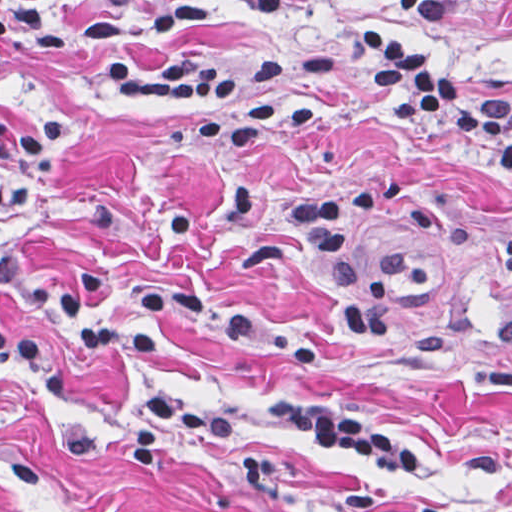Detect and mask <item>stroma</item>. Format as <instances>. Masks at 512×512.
Here are the masks:
<instances>
[{
  "label": "stroma",
  "mask_w": 512,
  "mask_h": 512,
  "mask_svg": "<svg viewBox=\"0 0 512 512\" xmlns=\"http://www.w3.org/2000/svg\"><path fill=\"white\" fill-rule=\"evenodd\" d=\"M151 1L46 0L41 35L0 49V122L69 110L76 124L54 177L13 211L12 240L58 268L108 267V300L131 318L159 279L203 282L208 300L144 360L60 356V389L0 366V512H512V178L488 177L459 129L399 120L344 62L250 89L312 106L308 129L213 152L190 113L119 95L102 42L82 38L78 25ZM212 2L117 44L138 68H247L380 29L512 100V0L452 25L429 23L420 0ZM151 385L235 428L170 436L150 469H130L121 442ZM269 394L354 415L440 469L322 450Z\"/></svg>",
  "instance_id": "stroma-1"
}]
</instances>
